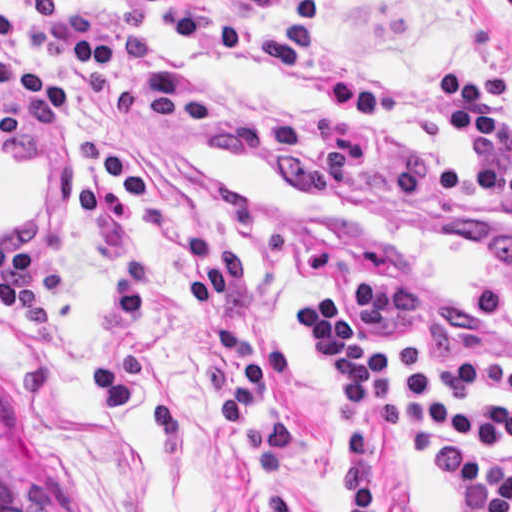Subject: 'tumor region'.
Instances as JSON below:
<instances>
[{"label": "tumor region", "mask_w": 512, "mask_h": 512, "mask_svg": "<svg viewBox=\"0 0 512 512\" xmlns=\"http://www.w3.org/2000/svg\"><path fill=\"white\" fill-rule=\"evenodd\" d=\"M0 512H41L37 501L19 489L1 468Z\"/></svg>", "instance_id": "1"}]
</instances>
